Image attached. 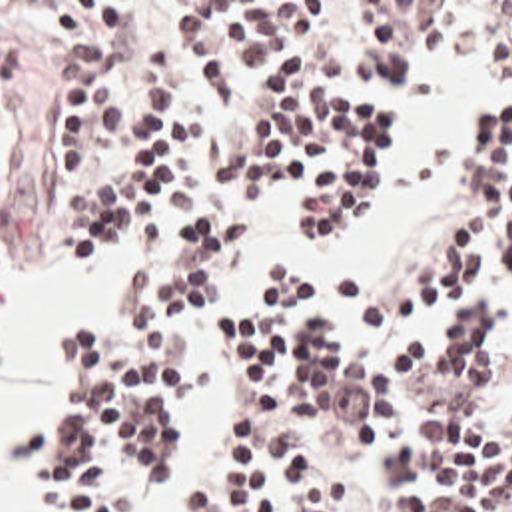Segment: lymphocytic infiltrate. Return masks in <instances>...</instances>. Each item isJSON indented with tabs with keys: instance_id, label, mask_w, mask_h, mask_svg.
Masks as SVG:
<instances>
[{
	"instance_id": "f902f5d3",
	"label": "lymphocytic infiltrate",
	"mask_w": 512,
	"mask_h": 512,
	"mask_svg": "<svg viewBox=\"0 0 512 512\" xmlns=\"http://www.w3.org/2000/svg\"><path fill=\"white\" fill-rule=\"evenodd\" d=\"M35 4L63 58L83 64L59 88L63 166L47 190L63 262L93 268L125 244L157 258L193 222L173 284L141 262L115 276L105 319L63 335L59 391L23 437L43 512H123L177 427L189 335L257 202L293 186L315 234L341 240L365 226L391 142L381 118L311 82L333 2L189 4L181 36L207 100L243 118L233 126L201 124L179 90L115 112L101 80L169 66L171 36L143 2ZM417 44L512 68V2H353L341 76L377 88ZM15 74L0 44V118ZM465 174L467 228L429 278L373 298L351 270L343 306L369 339H343L319 294L283 280L233 313L243 451L191 512H512V397L475 419L501 391L512 335V108L469 132Z\"/></svg>"
}]
</instances>
